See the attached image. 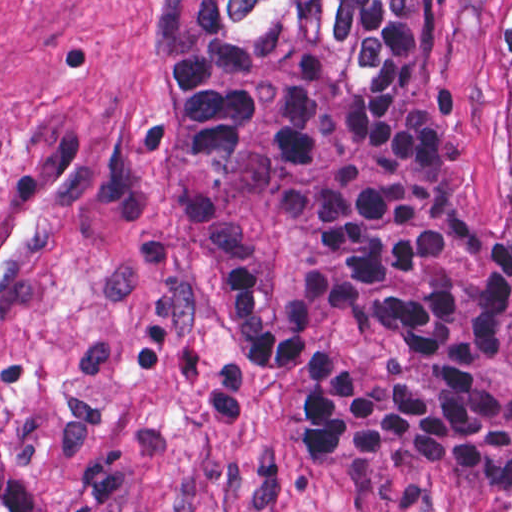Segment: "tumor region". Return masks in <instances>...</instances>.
<instances>
[{
    "instance_id": "obj_1",
    "label": "tumor region",
    "mask_w": 512,
    "mask_h": 512,
    "mask_svg": "<svg viewBox=\"0 0 512 512\" xmlns=\"http://www.w3.org/2000/svg\"><path fill=\"white\" fill-rule=\"evenodd\" d=\"M512 111V0H490ZM149 58L213 291L319 476L443 472L512 512V230L436 157L433 0H154ZM0 512H51L0 455Z\"/></svg>"
}]
</instances>
